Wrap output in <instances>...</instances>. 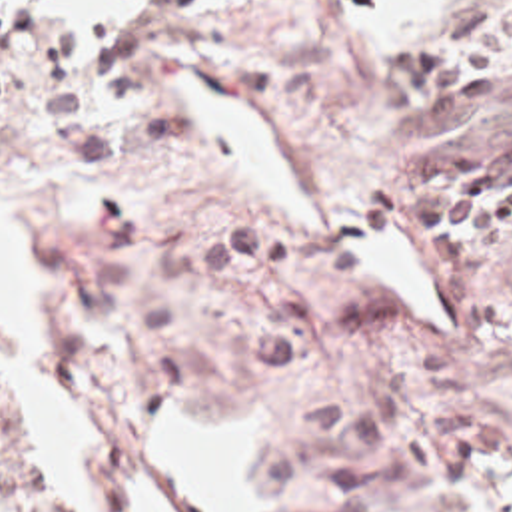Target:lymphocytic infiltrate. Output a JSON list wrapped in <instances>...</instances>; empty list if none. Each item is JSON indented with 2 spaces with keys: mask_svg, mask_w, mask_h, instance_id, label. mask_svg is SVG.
I'll return each mask as SVG.
<instances>
[{
  "mask_svg": "<svg viewBox=\"0 0 512 512\" xmlns=\"http://www.w3.org/2000/svg\"><path fill=\"white\" fill-rule=\"evenodd\" d=\"M34 45V21L28 11L0 0V101L16 87L18 73Z\"/></svg>",
  "mask_w": 512,
  "mask_h": 512,
  "instance_id": "obj_1",
  "label": "lymphocytic infiltrate"
}]
</instances>
